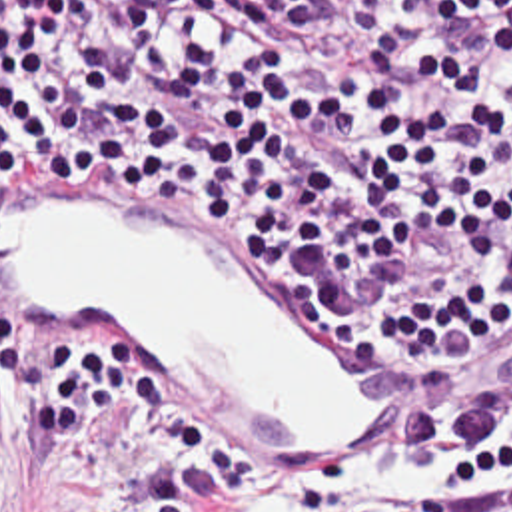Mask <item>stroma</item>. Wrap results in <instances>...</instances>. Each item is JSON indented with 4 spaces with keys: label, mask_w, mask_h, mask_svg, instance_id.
Listing matches in <instances>:
<instances>
[{
    "label": "stroma",
    "mask_w": 512,
    "mask_h": 512,
    "mask_svg": "<svg viewBox=\"0 0 512 512\" xmlns=\"http://www.w3.org/2000/svg\"><path fill=\"white\" fill-rule=\"evenodd\" d=\"M78 205L0 209V285L92 317H128L200 417L300 469H322L373 425L351 335L280 283L120 199L94 147H60ZM512 377V355L415 383L413 401ZM140 405L102 411L80 451H48L0 385V512H134L160 475ZM202 512L282 511L222 503Z\"/></svg>",
    "instance_id": "obj_1"
}]
</instances>
